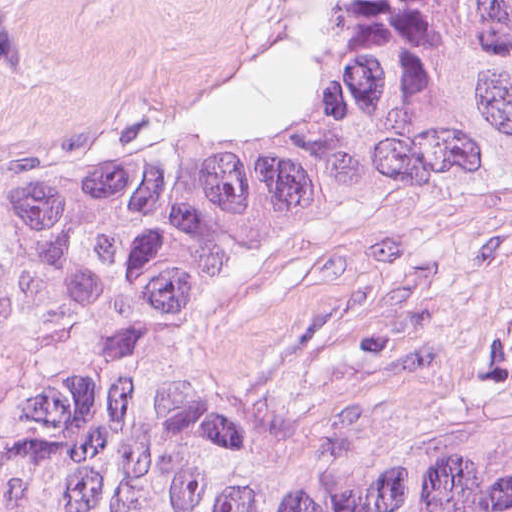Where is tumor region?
<instances>
[{"label": "tumor region", "mask_w": 512, "mask_h": 512, "mask_svg": "<svg viewBox=\"0 0 512 512\" xmlns=\"http://www.w3.org/2000/svg\"><path fill=\"white\" fill-rule=\"evenodd\" d=\"M512 210V0H306L237 110L0 173V512H512V357L203 332L409 205Z\"/></svg>", "instance_id": "tumor-region-1"}]
</instances>
